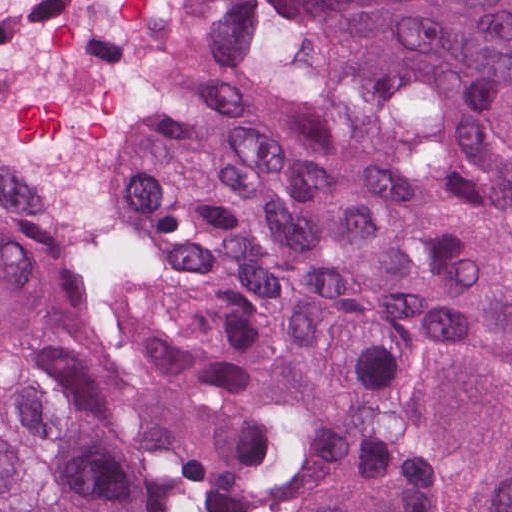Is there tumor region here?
Here are the masks:
<instances>
[{
    "mask_svg": "<svg viewBox=\"0 0 512 512\" xmlns=\"http://www.w3.org/2000/svg\"><path fill=\"white\" fill-rule=\"evenodd\" d=\"M125 227L117 353L0 156V512H202L170 430L304 448L300 512H512V0H225Z\"/></svg>",
    "mask_w": 512,
    "mask_h": 512,
    "instance_id": "1",
    "label": "tumor region"
}]
</instances>
